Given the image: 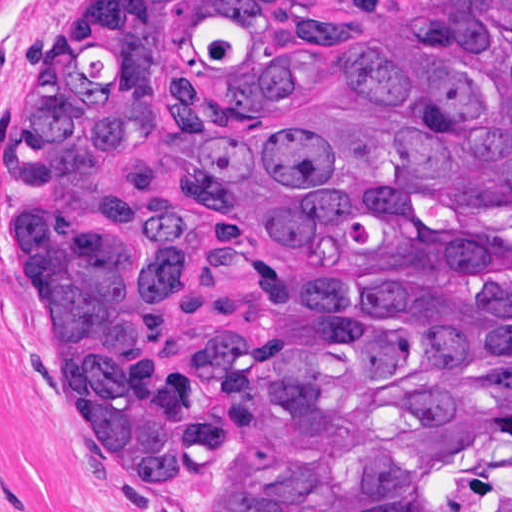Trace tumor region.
<instances>
[{"instance_id": "1", "label": "tumor region", "mask_w": 512, "mask_h": 512, "mask_svg": "<svg viewBox=\"0 0 512 512\" xmlns=\"http://www.w3.org/2000/svg\"><path fill=\"white\" fill-rule=\"evenodd\" d=\"M16 229L160 512H512V0H84Z\"/></svg>"}]
</instances>
